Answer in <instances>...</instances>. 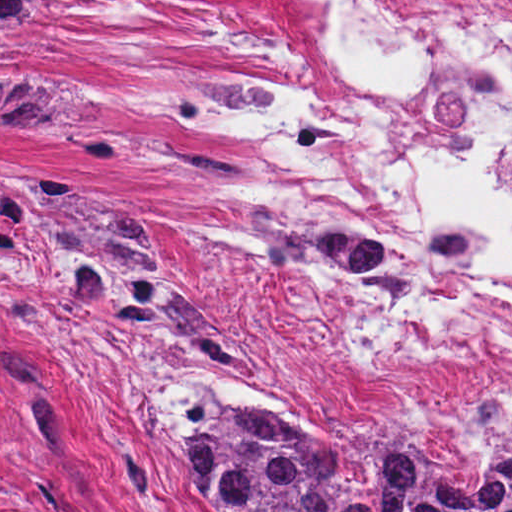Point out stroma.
<instances>
[{"instance_id": "35a3bbf8", "label": "stroma", "mask_w": 512, "mask_h": 512, "mask_svg": "<svg viewBox=\"0 0 512 512\" xmlns=\"http://www.w3.org/2000/svg\"><path fill=\"white\" fill-rule=\"evenodd\" d=\"M337 10L335 0H71L13 41L26 71L78 100L60 118L0 106V512H206L150 405L188 379L277 409L338 445L392 422L424 457L467 478L512 429V399L463 426L354 395L270 304V287L301 268L345 300L402 293L346 267L261 258L239 205L272 225L382 248L407 291L402 241L287 156L251 98L273 46L309 40ZM193 79L228 85L201 95L199 123L131 96ZM53 131H133L213 154L233 180L219 184L176 155L88 162ZM24 169L90 181L137 224L193 292L178 299L170 329L120 325L85 305L32 223Z\"/></svg>"}]
</instances>
